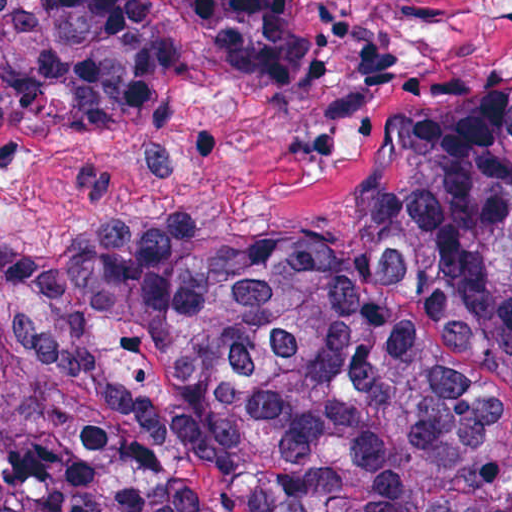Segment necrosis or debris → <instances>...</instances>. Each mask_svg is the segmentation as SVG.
<instances>
[{"instance_id":"4bbe7bcc","label":"necrosis or debris","mask_w":512,"mask_h":512,"mask_svg":"<svg viewBox=\"0 0 512 512\" xmlns=\"http://www.w3.org/2000/svg\"><path fill=\"white\" fill-rule=\"evenodd\" d=\"M82 193L78 162L61 144L0 126V220L46 230Z\"/></svg>"}]
</instances>
